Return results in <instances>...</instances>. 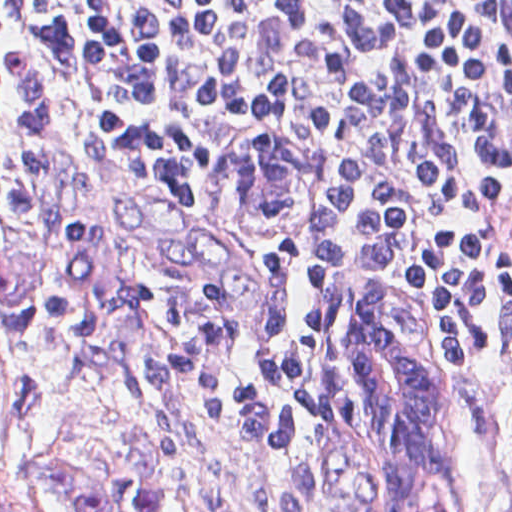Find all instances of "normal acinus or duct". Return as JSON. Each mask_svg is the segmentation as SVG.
<instances>
[{"instance_id":"30e58d81","label":"normal acinus or duct","mask_w":512,"mask_h":512,"mask_svg":"<svg viewBox=\"0 0 512 512\" xmlns=\"http://www.w3.org/2000/svg\"><path fill=\"white\" fill-rule=\"evenodd\" d=\"M282 134L239 140L233 153L236 209L253 218H288L300 200V152Z\"/></svg>"}]
</instances>
